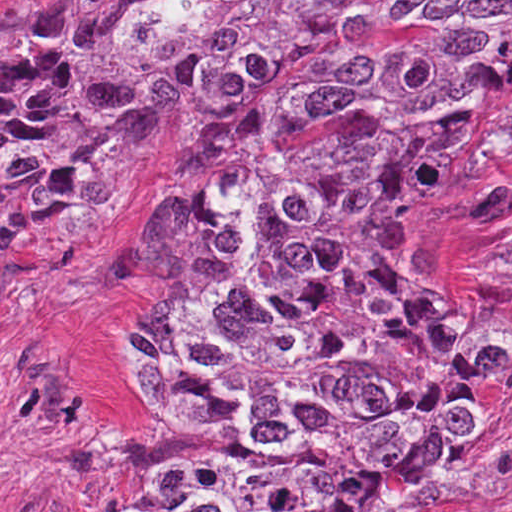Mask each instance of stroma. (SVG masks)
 Listing matches in <instances>:
<instances>
[{
    "instance_id": "obj_1",
    "label": "stroma",
    "mask_w": 512,
    "mask_h": 512,
    "mask_svg": "<svg viewBox=\"0 0 512 512\" xmlns=\"http://www.w3.org/2000/svg\"><path fill=\"white\" fill-rule=\"evenodd\" d=\"M71 1L0 0V20L38 27ZM205 134L203 118L146 105L125 192L0 281V512H97L109 481L205 439L135 362L146 229ZM418 285L452 329L472 315L512 322V169L440 212L415 247ZM496 394L439 512H512V366Z\"/></svg>"
}]
</instances>
